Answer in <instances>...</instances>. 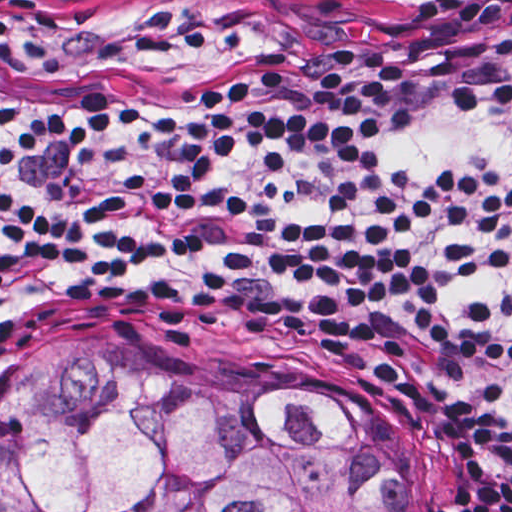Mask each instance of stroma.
Wrapping results in <instances>:
<instances>
[{
    "instance_id": "35a3bbf8",
    "label": "stroma",
    "mask_w": 512,
    "mask_h": 512,
    "mask_svg": "<svg viewBox=\"0 0 512 512\" xmlns=\"http://www.w3.org/2000/svg\"><path fill=\"white\" fill-rule=\"evenodd\" d=\"M83 3L92 0H14ZM312 14H412L449 0H273ZM113 340L234 377H294L345 386L383 407L401 444L417 512H512V495L398 360L342 335L273 332L142 311H56L1 324L0 0V512L1 396L38 344Z\"/></svg>"
}]
</instances>
